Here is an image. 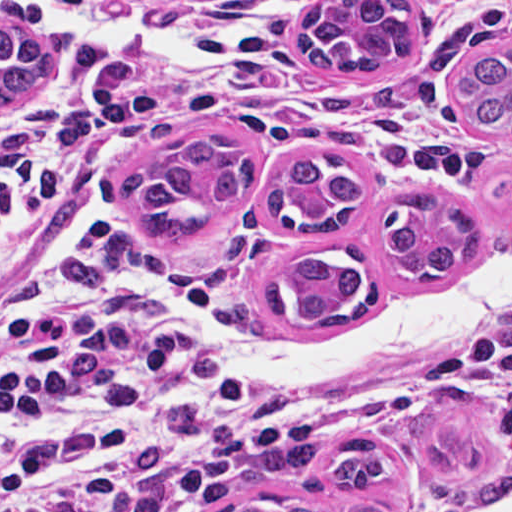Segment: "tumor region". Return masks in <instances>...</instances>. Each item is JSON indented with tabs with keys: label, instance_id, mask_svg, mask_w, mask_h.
Returning <instances> with one entry per match:
<instances>
[{
	"label": "tumor region",
	"instance_id": "tumor-region-1",
	"mask_svg": "<svg viewBox=\"0 0 512 512\" xmlns=\"http://www.w3.org/2000/svg\"><path fill=\"white\" fill-rule=\"evenodd\" d=\"M412 0H327L302 13L290 29L295 54L317 71H367L406 62L414 53ZM71 45L56 27L34 39L0 26V106L20 101L53 74ZM457 98L474 127L512 132V45L486 49L459 70ZM254 181L246 141L222 124H205L174 140L165 159L132 171L118 200L140 219V233L163 246H196L215 211H229ZM363 198V179L348 160L303 155L288 160L270 185L268 211L294 236L335 230ZM381 258L403 284H433L481 248L474 209L433 188L392 199L379 229ZM367 293L363 256L356 249L298 247L276 270L266 305L279 318L323 325L361 303ZM484 408L464 389L432 393L406 421L409 444L426 467L435 498L484 506L512 494V468L485 454L479 423ZM395 470L386 444L357 437L343 442L325 469L332 489H378ZM224 512H381L370 504L308 503L253 497Z\"/></svg>",
	"mask_w": 512,
	"mask_h": 512
}]
</instances>
